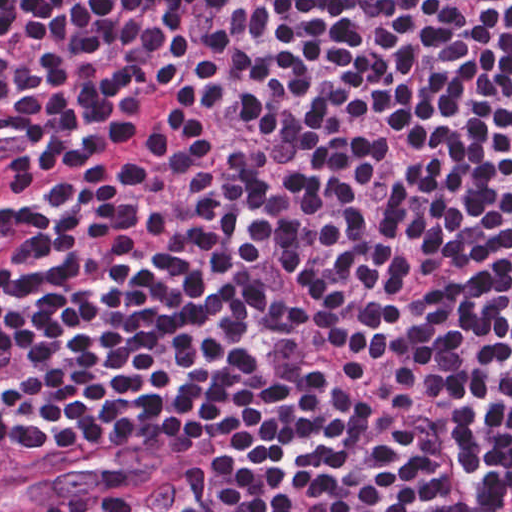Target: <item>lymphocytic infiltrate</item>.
<instances>
[{"mask_svg": "<svg viewBox=\"0 0 512 512\" xmlns=\"http://www.w3.org/2000/svg\"><path fill=\"white\" fill-rule=\"evenodd\" d=\"M512 410V0H0V484L420 512Z\"/></svg>", "mask_w": 512, "mask_h": 512, "instance_id": "obj_1", "label": "lymphocytic infiltrate"}]
</instances>
